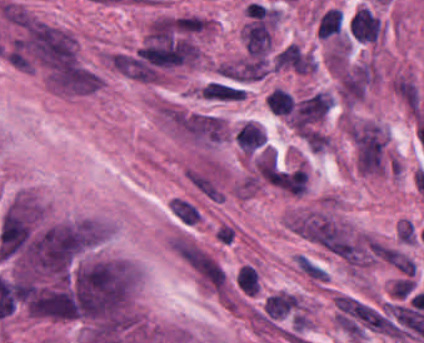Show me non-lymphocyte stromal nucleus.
<instances>
[{
	"mask_svg": "<svg viewBox=\"0 0 424 343\" xmlns=\"http://www.w3.org/2000/svg\"><path fill=\"white\" fill-rule=\"evenodd\" d=\"M170 246L201 283L211 289L226 286V269L210 250L187 235H174Z\"/></svg>",
	"mask_w": 424,
	"mask_h": 343,
	"instance_id": "1",
	"label": "non-lymphocyte stromal nucleus"
},
{
	"mask_svg": "<svg viewBox=\"0 0 424 343\" xmlns=\"http://www.w3.org/2000/svg\"><path fill=\"white\" fill-rule=\"evenodd\" d=\"M167 207L174 219L184 225L197 226L202 218L200 205L182 195L173 196Z\"/></svg>",
	"mask_w": 424,
	"mask_h": 343,
	"instance_id": "2",
	"label": "non-lymphocyte stromal nucleus"
},
{
	"mask_svg": "<svg viewBox=\"0 0 424 343\" xmlns=\"http://www.w3.org/2000/svg\"><path fill=\"white\" fill-rule=\"evenodd\" d=\"M203 92L206 96L226 98V99H240L245 96L241 86L210 80L202 86Z\"/></svg>",
	"mask_w": 424,
	"mask_h": 343,
	"instance_id": "3",
	"label": "non-lymphocyte stromal nucleus"
},
{
	"mask_svg": "<svg viewBox=\"0 0 424 343\" xmlns=\"http://www.w3.org/2000/svg\"><path fill=\"white\" fill-rule=\"evenodd\" d=\"M340 91L354 100L362 96L356 68L340 84Z\"/></svg>",
	"mask_w": 424,
	"mask_h": 343,
	"instance_id": "4",
	"label": "non-lymphocyte stromal nucleus"
}]
</instances>
